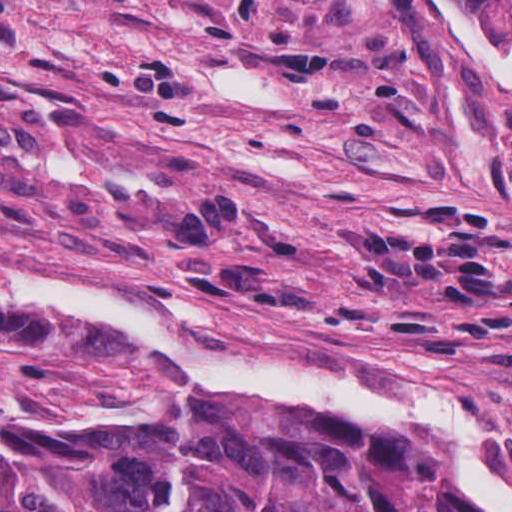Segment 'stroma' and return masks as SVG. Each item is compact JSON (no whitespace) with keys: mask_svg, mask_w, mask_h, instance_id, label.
Wrapping results in <instances>:
<instances>
[{"mask_svg":"<svg viewBox=\"0 0 512 512\" xmlns=\"http://www.w3.org/2000/svg\"><path fill=\"white\" fill-rule=\"evenodd\" d=\"M0 263L227 354L439 387L512 476V87L422 0H0ZM172 397L212 398L115 337L0 313L1 410Z\"/></svg>","mask_w":512,"mask_h":512,"instance_id":"obj_1","label":"stroma"}]
</instances>
